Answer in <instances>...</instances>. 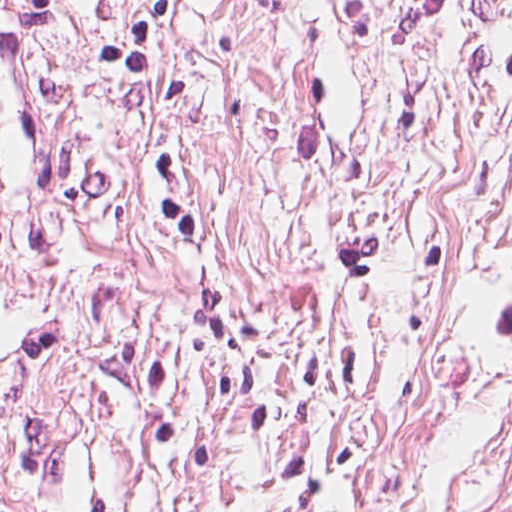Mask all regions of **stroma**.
<instances>
[{
  "instance_id": "1",
  "label": "stroma",
  "mask_w": 512,
  "mask_h": 512,
  "mask_svg": "<svg viewBox=\"0 0 512 512\" xmlns=\"http://www.w3.org/2000/svg\"><path fill=\"white\" fill-rule=\"evenodd\" d=\"M0 219V512H512V0H44Z\"/></svg>"
}]
</instances>
